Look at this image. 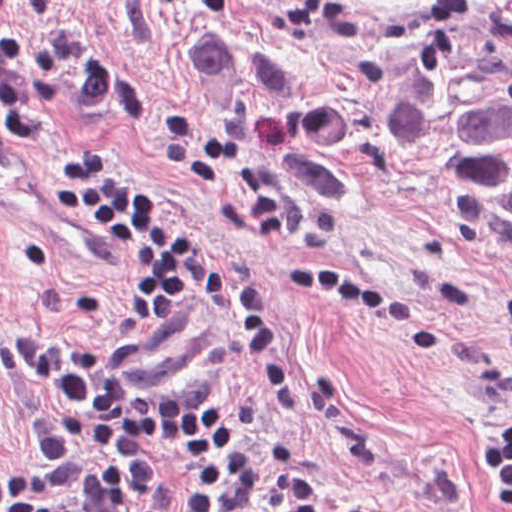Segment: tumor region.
<instances>
[{"label":"tumor region","instance_id":"e687c5a6","mask_svg":"<svg viewBox=\"0 0 512 512\" xmlns=\"http://www.w3.org/2000/svg\"><path fill=\"white\" fill-rule=\"evenodd\" d=\"M385 135L449 215L512 252V0H482L414 56Z\"/></svg>","mask_w":512,"mask_h":512}]
</instances>
